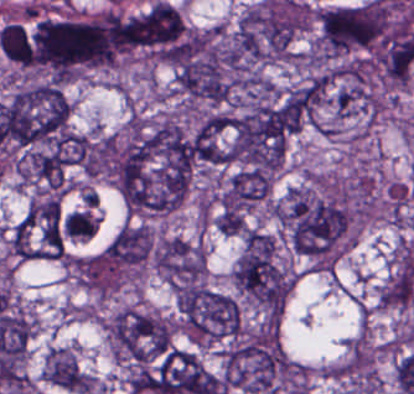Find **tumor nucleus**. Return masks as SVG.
Wrapping results in <instances>:
<instances>
[{"mask_svg": "<svg viewBox=\"0 0 414 394\" xmlns=\"http://www.w3.org/2000/svg\"><path fill=\"white\" fill-rule=\"evenodd\" d=\"M414 295V269L394 265L377 288L376 301L381 306H403Z\"/></svg>", "mask_w": 414, "mask_h": 394, "instance_id": "feef74b5", "label": "tumor nucleus"}, {"mask_svg": "<svg viewBox=\"0 0 414 394\" xmlns=\"http://www.w3.org/2000/svg\"><path fill=\"white\" fill-rule=\"evenodd\" d=\"M183 34L184 25L177 10L159 1L129 16L126 23L129 49L169 62Z\"/></svg>", "mask_w": 414, "mask_h": 394, "instance_id": "2083b535", "label": "tumor nucleus"}, {"mask_svg": "<svg viewBox=\"0 0 414 394\" xmlns=\"http://www.w3.org/2000/svg\"><path fill=\"white\" fill-rule=\"evenodd\" d=\"M319 45L326 54L367 47L386 31L388 4L370 0L325 6L317 14Z\"/></svg>", "mask_w": 414, "mask_h": 394, "instance_id": "5ab6c2c4", "label": "tumor nucleus"}, {"mask_svg": "<svg viewBox=\"0 0 414 394\" xmlns=\"http://www.w3.org/2000/svg\"><path fill=\"white\" fill-rule=\"evenodd\" d=\"M268 184L269 170L248 166L237 170L219 197L220 205L247 211L267 193Z\"/></svg>", "mask_w": 414, "mask_h": 394, "instance_id": "c2bd9aea", "label": "tumor nucleus"}, {"mask_svg": "<svg viewBox=\"0 0 414 394\" xmlns=\"http://www.w3.org/2000/svg\"><path fill=\"white\" fill-rule=\"evenodd\" d=\"M93 217L94 212L92 208L83 207L70 238L83 239Z\"/></svg>", "mask_w": 414, "mask_h": 394, "instance_id": "f7901128", "label": "tumor nucleus"}, {"mask_svg": "<svg viewBox=\"0 0 414 394\" xmlns=\"http://www.w3.org/2000/svg\"><path fill=\"white\" fill-rule=\"evenodd\" d=\"M159 275L171 286L198 284L203 275V256L192 242L179 237H159L153 248Z\"/></svg>", "mask_w": 414, "mask_h": 394, "instance_id": "8087334f", "label": "tumor nucleus"}, {"mask_svg": "<svg viewBox=\"0 0 414 394\" xmlns=\"http://www.w3.org/2000/svg\"><path fill=\"white\" fill-rule=\"evenodd\" d=\"M174 303L190 338L213 341L239 331V305L231 294L189 283L176 288Z\"/></svg>", "mask_w": 414, "mask_h": 394, "instance_id": "2cbd58db", "label": "tumor nucleus"}, {"mask_svg": "<svg viewBox=\"0 0 414 394\" xmlns=\"http://www.w3.org/2000/svg\"><path fill=\"white\" fill-rule=\"evenodd\" d=\"M232 277L255 299L284 304V277L272 237L247 234Z\"/></svg>", "mask_w": 414, "mask_h": 394, "instance_id": "3d1891a8", "label": "tumor nucleus"}, {"mask_svg": "<svg viewBox=\"0 0 414 394\" xmlns=\"http://www.w3.org/2000/svg\"><path fill=\"white\" fill-rule=\"evenodd\" d=\"M34 67L70 80L112 58L110 22L104 15L40 16L33 28Z\"/></svg>", "mask_w": 414, "mask_h": 394, "instance_id": "2f306a5c", "label": "tumor nucleus"}, {"mask_svg": "<svg viewBox=\"0 0 414 394\" xmlns=\"http://www.w3.org/2000/svg\"><path fill=\"white\" fill-rule=\"evenodd\" d=\"M215 227L225 235H236L247 225L242 211L236 208H222L215 219Z\"/></svg>", "mask_w": 414, "mask_h": 394, "instance_id": "3e47fb67", "label": "tumor nucleus"}, {"mask_svg": "<svg viewBox=\"0 0 414 394\" xmlns=\"http://www.w3.org/2000/svg\"><path fill=\"white\" fill-rule=\"evenodd\" d=\"M69 104L60 87L34 84L5 104L0 139L16 149L51 146L67 134Z\"/></svg>", "mask_w": 414, "mask_h": 394, "instance_id": "8643909e", "label": "tumor nucleus"}]
</instances>
